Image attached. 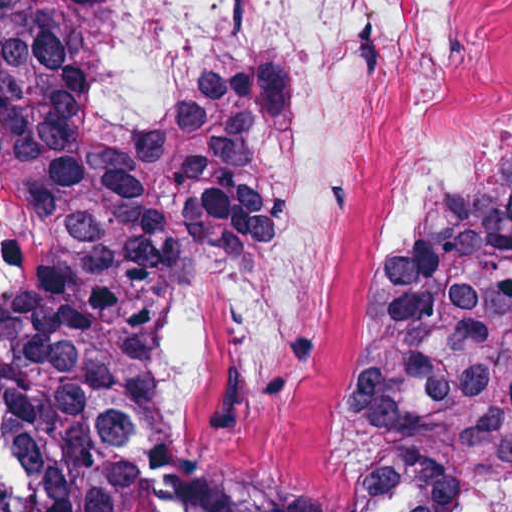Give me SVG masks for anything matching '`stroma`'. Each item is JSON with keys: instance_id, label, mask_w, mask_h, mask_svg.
<instances>
[{"instance_id": "stroma-1", "label": "stroma", "mask_w": 512, "mask_h": 512, "mask_svg": "<svg viewBox=\"0 0 512 512\" xmlns=\"http://www.w3.org/2000/svg\"><path fill=\"white\" fill-rule=\"evenodd\" d=\"M301 107L271 124L291 133ZM511 151L478 163L461 181ZM155 344L92 408L102 463L123 512H331L323 464L250 471L184 424L152 369Z\"/></svg>"}]
</instances>
